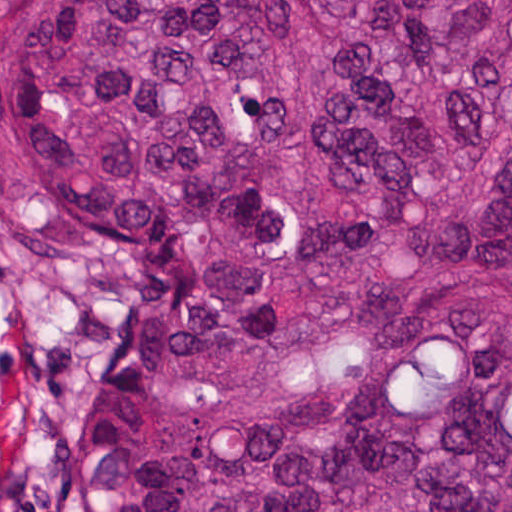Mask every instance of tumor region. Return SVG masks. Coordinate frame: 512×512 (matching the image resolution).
I'll return each instance as SVG.
<instances>
[{"instance_id":"e687c5a6","label":"tumor region","mask_w":512,"mask_h":512,"mask_svg":"<svg viewBox=\"0 0 512 512\" xmlns=\"http://www.w3.org/2000/svg\"><path fill=\"white\" fill-rule=\"evenodd\" d=\"M118 224L57 512H512V0H0Z\"/></svg>"}]
</instances>
